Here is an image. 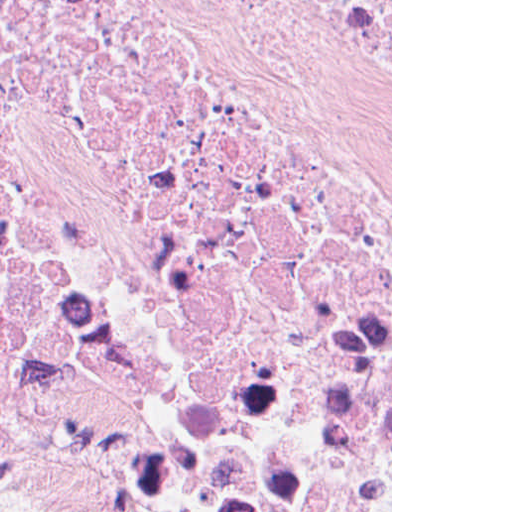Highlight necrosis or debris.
Here are the masks:
<instances>
[{"mask_svg": "<svg viewBox=\"0 0 512 512\" xmlns=\"http://www.w3.org/2000/svg\"><path fill=\"white\" fill-rule=\"evenodd\" d=\"M0 465L391 512V0H0Z\"/></svg>", "mask_w": 512, "mask_h": 512, "instance_id": "1", "label": "necrosis or debris"}]
</instances>
